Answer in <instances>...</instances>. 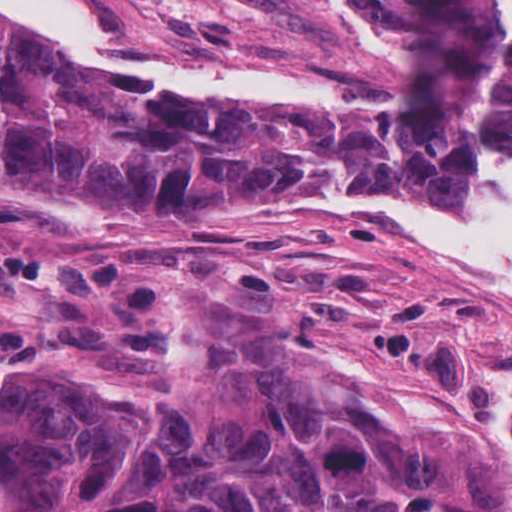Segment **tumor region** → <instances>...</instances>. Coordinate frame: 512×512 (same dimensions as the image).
I'll list each match as a JSON object with an SVG mask.
<instances>
[{
    "instance_id": "tumor-region-1",
    "label": "tumor region",
    "mask_w": 512,
    "mask_h": 512,
    "mask_svg": "<svg viewBox=\"0 0 512 512\" xmlns=\"http://www.w3.org/2000/svg\"><path fill=\"white\" fill-rule=\"evenodd\" d=\"M440 49L460 105L415 147L69 93L145 87L0 23V199L135 218L267 178L437 182L472 128L512 129V0H350ZM0 292L87 302L107 337H151L157 273L0 242ZM0 512H512V469L362 384L249 307L178 297L155 369L0 374Z\"/></svg>"
}]
</instances>
